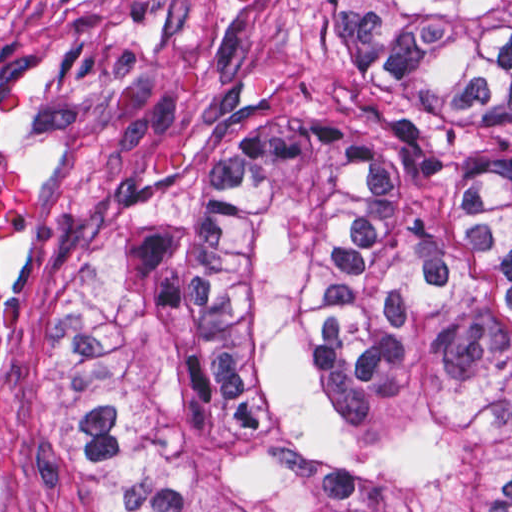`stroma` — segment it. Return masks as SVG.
<instances>
[{"label": "stroma", "instance_id": "stroma-1", "mask_svg": "<svg viewBox=\"0 0 512 512\" xmlns=\"http://www.w3.org/2000/svg\"><path fill=\"white\" fill-rule=\"evenodd\" d=\"M330 0H0V512H107L60 425L66 324L171 313L226 136L308 82Z\"/></svg>", "mask_w": 512, "mask_h": 512}]
</instances>
